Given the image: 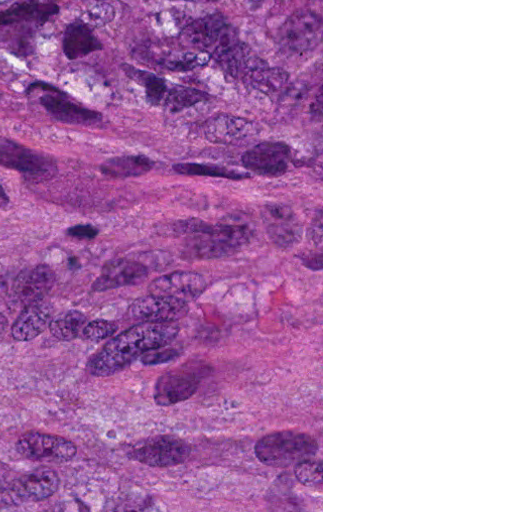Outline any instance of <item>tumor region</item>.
<instances>
[{
	"label": "tumor region",
	"mask_w": 512,
	"mask_h": 512,
	"mask_svg": "<svg viewBox=\"0 0 512 512\" xmlns=\"http://www.w3.org/2000/svg\"><path fill=\"white\" fill-rule=\"evenodd\" d=\"M0 512H161V0H0Z\"/></svg>",
	"instance_id": "1"
}]
</instances>
